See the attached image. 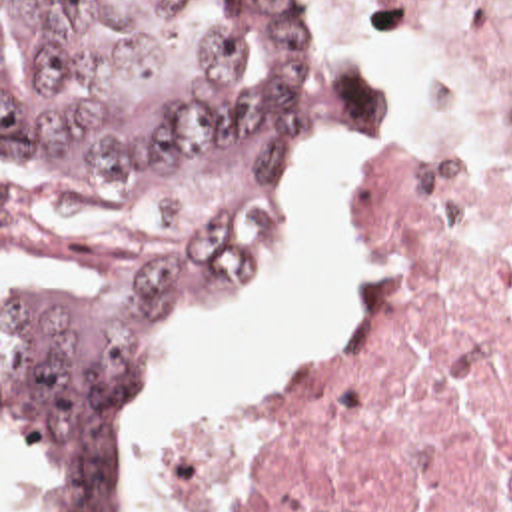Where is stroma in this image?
Segmentation results:
<instances>
[{
  "label": "stroma",
  "instance_id": "1",
  "mask_svg": "<svg viewBox=\"0 0 512 512\" xmlns=\"http://www.w3.org/2000/svg\"><path fill=\"white\" fill-rule=\"evenodd\" d=\"M308 12L311 16V24H313V32H315V38L321 46V50L333 58L341 68L353 72L343 60H339L337 56L329 54L327 52V42H325V28H323V22H321V14H319V8L313 6L310 2L304 1ZM409 22L433 44V50H435V112L439 108V102H441V94L455 70L457 64H463L459 60V56L453 52V48L425 22V20H415V18H409ZM357 74L359 78L367 80L373 84V132L369 134H361V136H353V138H347V140H339V142H333V144H325V146H319V148H311V150H304L300 152L296 158H292L276 186V192L272 196V202H270V230L274 226V220H276V212L280 210L282 206V200H284V192L292 180V176L296 174V170L300 168V164L304 160H308L311 156H317V154H325V152H333V150H343V148H353L377 134H381L383 130V122H385V116L389 112V104H391V94H389V86H387V78L385 74H371V72H353ZM479 96H481V106H483V112H485V118H487V150L481 152V154H465L463 150H459L453 142H449L447 138L443 136H437V134H417V132H383L379 136V140L375 142L373 150H371V168L369 172L363 176V180L357 184V188L353 190V196H351V206H349V216L353 214L355 220L359 222L361 230H363V198H365V190L369 186V182L377 176L385 156L399 144H405V142H411L415 138H435V140H441L453 154V158L459 162V166L463 168H469V170H477V172H495L499 168H505L512 164V112H509L505 106H501L499 102H495L493 98H489L483 88L479 86ZM0 160H2V0H0ZM268 230V234H270ZM266 242H268V236H266ZM266 242H264V248L260 252V258L250 274V278H254L262 266V260H264V252H266ZM375 258V256H373ZM375 270H377V264H375ZM248 278V280H250ZM244 288V286H242ZM240 288V290H242ZM236 298V296H234ZM234 298H228V300H218V302H210L194 312H190L186 318H182L176 328L170 332L168 336V344H166V352L152 376V382H150V390H148V398L146 402L142 404V408L132 416V420L128 422V452H130V464H132V424L136 420H140L154 404L156 400V382H158V376L162 372V368L166 366L168 358L174 354V350L188 338L192 326L206 314L210 312H216L220 308H224L226 304H230ZM363 318V304L359 308V314H357V320H355V326L347 338V342L351 340V336L355 334L359 322ZM345 342V344H347ZM343 344V346H345ZM282 390L270 394V396H262V398H252V400H246V402H238V404H230V406H220V408H200L196 412H190V414H184L176 420H172L166 428V460H164V486H162V512H182L180 510V502L176 498V462H174V450H172V432L188 422V420H194V418H200V416H222V414H236V412H246V410H252V408H258V406H264V404H270L274 400H278ZM0 426H2V304H0ZM132 478H134V512H144V504L138 496V480H136V470L132 466ZM224 512V510H222Z\"/></svg>",
  "mask_w": 512,
  "mask_h": 512
}]
</instances>
